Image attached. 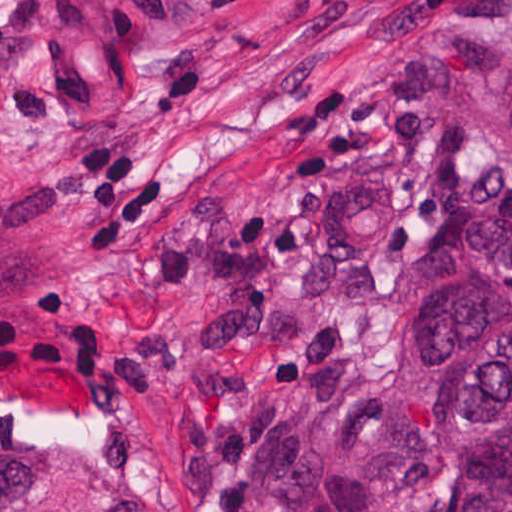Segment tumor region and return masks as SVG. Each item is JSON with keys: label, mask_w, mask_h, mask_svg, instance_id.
<instances>
[{"label": "tumor region", "mask_w": 512, "mask_h": 512, "mask_svg": "<svg viewBox=\"0 0 512 512\" xmlns=\"http://www.w3.org/2000/svg\"><path fill=\"white\" fill-rule=\"evenodd\" d=\"M91 1L120 35L190 18L200 2ZM434 68L512 182V35L440 29ZM230 477L284 512H512V226L448 237L416 265L323 454L297 433L245 428ZM0 512L153 511L140 497L70 505L2 445Z\"/></svg>", "instance_id": "1"}]
</instances>
